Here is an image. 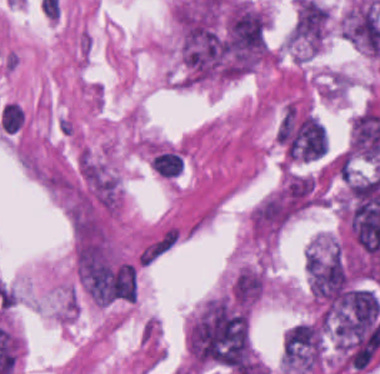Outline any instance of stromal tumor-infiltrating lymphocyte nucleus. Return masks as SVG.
Instances as JSON below:
<instances>
[{"label":"stromal tumor-infiltrating lymphocyte nucleus","instance_id":"bc302bb0","mask_svg":"<svg viewBox=\"0 0 380 374\" xmlns=\"http://www.w3.org/2000/svg\"><path fill=\"white\" fill-rule=\"evenodd\" d=\"M24 115L20 106L13 102L4 104L0 112V121L8 131H16L23 123Z\"/></svg>","mask_w":380,"mask_h":374}]
</instances>
